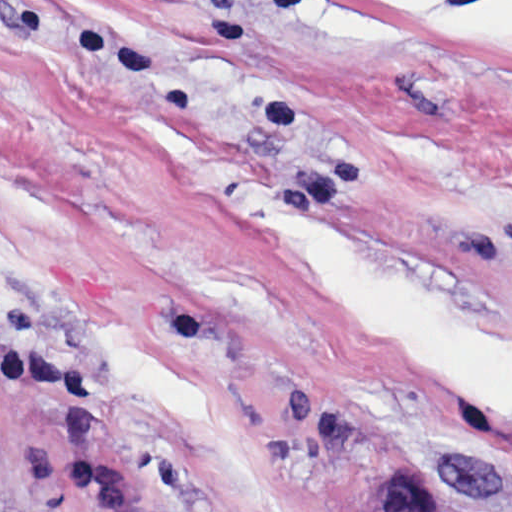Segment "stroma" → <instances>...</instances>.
I'll list each match as a JSON object with an SVG mask.
<instances>
[{
    "instance_id": "stroma-1",
    "label": "stroma",
    "mask_w": 512,
    "mask_h": 512,
    "mask_svg": "<svg viewBox=\"0 0 512 512\" xmlns=\"http://www.w3.org/2000/svg\"><path fill=\"white\" fill-rule=\"evenodd\" d=\"M0 307L148 512H512V0H0Z\"/></svg>"
}]
</instances>
